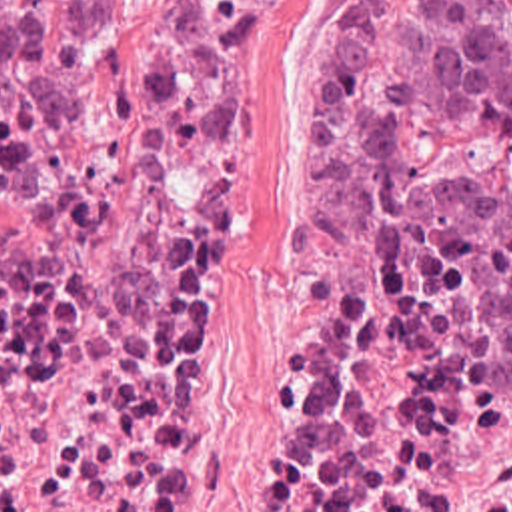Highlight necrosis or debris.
Segmentation results:
<instances>
[{
    "instance_id": "4bbe7bcc",
    "label": "necrosis or debris",
    "mask_w": 512,
    "mask_h": 512,
    "mask_svg": "<svg viewBox=\"0 0 512 512\" xmlns=\"http://www.w3.org/2000/svg\"><path fill=\"white\" fill-rule=\"evenodd\" d=\"M271 1L165 0L103 71L0 99V512H159ZM247 512H512V347L431 319L367 217L287 257Z\"/></svg>"
}]
</instances>
